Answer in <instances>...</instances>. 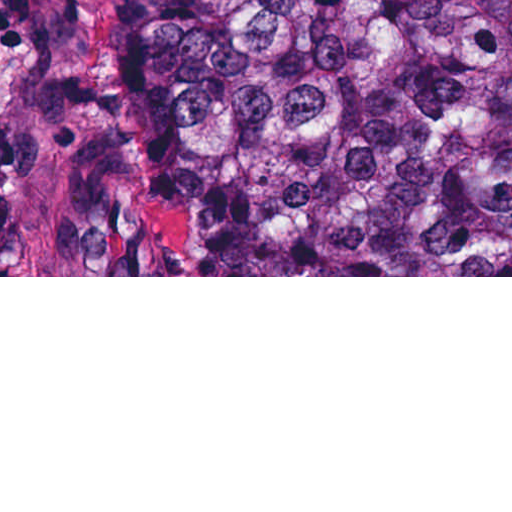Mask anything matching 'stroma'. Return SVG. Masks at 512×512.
Instances as JSON below:
<instances>
[{"label": "stroma", "instance_id": "obj_1", "mask_svg": "<svg viewBox=\"0 0 512 512\" xmlns=\"http://www.w3.org/2000/svg\"><path fill=\"white\" fill-rule=\"evenodd\" d=\"M149 65V0H0V143L13 170L124 183ZM0 277H512L46 275Z\"/></svg>", "mask_w": 512, "mask_h": 512}]
</instances>
